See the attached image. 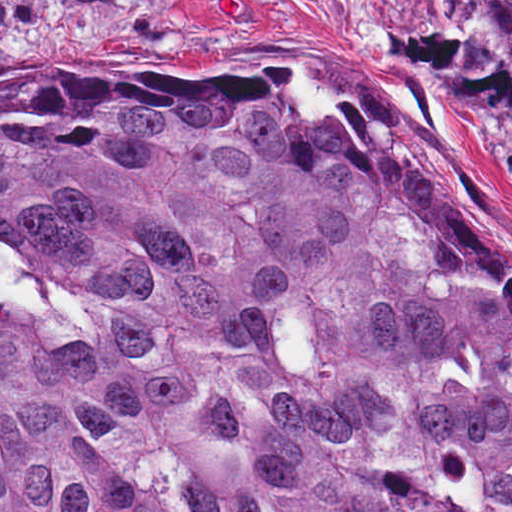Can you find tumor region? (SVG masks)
<instances>
[{
	"mask_svg": "<svg viewBox=\"0 0 512 512\" xmlns=\"http://www.w3.org/2000/svg\"><path fill=\"white\" fill-rule=\"evenodd\" d=\"M370 12L512 103V1ZM0 512H512V264L292 70L0 74Z\"/></svg>",
	"mask_w": 512,
	"mask_h": 512,
	"instance_id": "tumor-region-1",
	"label": "tumor region"
}]
</instances>
